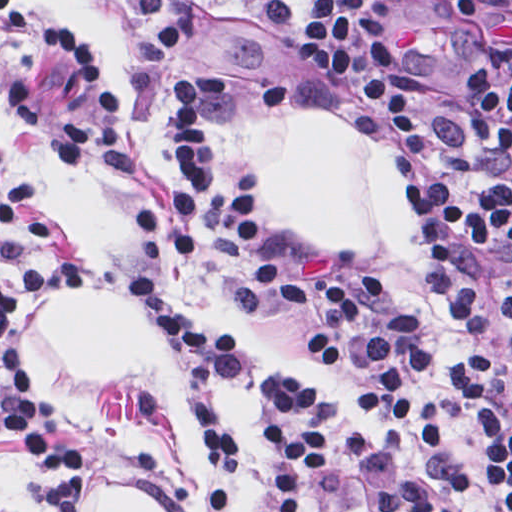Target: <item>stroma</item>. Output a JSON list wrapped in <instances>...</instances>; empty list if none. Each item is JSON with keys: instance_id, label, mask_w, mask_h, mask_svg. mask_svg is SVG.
Returning <instances> with one entry per match:
<instances>
[{"instance_id": "1", "label": "stroma", "mask_w": 512, "mask_h": 512, "mask_svg": "<svg viewBox=\"0 0 512 512\" xmlns=\"http://www.w3.org/2000/svg\"><path fill=\"white\" fill-rule=\"evenodd\" d=\"M121 21L141 55L139 125L127 113L105 54L91 28L56 0H0L50 35L89 72L93 94L76 88H34L0 70V208L12 189L30 181L55 227L43 256L86 267L94 285L119 289L137 267L163 253L134 226L130 210L158 195L168 150V87L184 64H204L218 92V133L226 162L248 190L268 230L303 266L314 271H372L363 255L312 250L273 215L259 186L258 165L240 137L249 113H305L339 121L393 154L401 146L365 91L346 77L302 68L220 21L198 5L180 20L149 29L116 0H84ZM417 234V232H416ZM421 245L425 267L439 292L444 316L459 333L440 282ZM185 283L234 325L240 370L208 378L189 362L153 320L157 341L185 397L201 453V512H212L205 493L202 440L193 416L197 394H208L217 422L240 443L237 498L230 512H271L270 462L262 436V391L286 374L305 381L312 412L347 419L357 409L336 386L320 382L303 364L308 324L265 310L240 252L214 223L209 239L183 253ZM22 274V264H0V286ZM474 276L489 316V340L508 397L512 378V271ZM56 297V296H55ZM53 298V297H51ZM49 298V299H51ZM48 300V299H47ZM46 301V300H45ZM44 301L23 309L14 327L24 364L43 391L63 440L92 450L95 484L129 489L161 512H200L197 486L174 441L162 398L149 388L90 378L53 359L40 341ZM414 315L428 343L425 372L432 399L455 372L459 354L439 351L430 327L391 290L372 316ZM400 471L428 478L458 512H492L476 441L456 420L447 448L378 437L355 458L328 464L317 492L319 512H374L372 485ZM31 464L21 440L0 437V512H40L29 497Z\"/></svg>"}]
</instances>
